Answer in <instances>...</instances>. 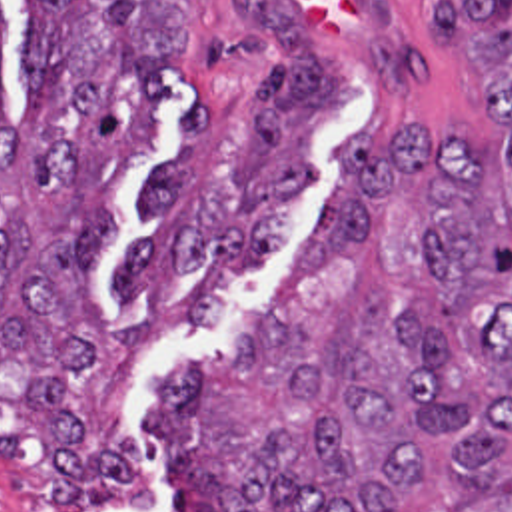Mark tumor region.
Returning <instances> with one entry per match:
<instances>
[{
    "mask_svg": "<svg viewBox=\"0 0 512 512\" xmlns=\"http://www.w3.org/2000/svg\"><path fill=\"white\" fill-rule=\"evenodd\" d=\"M432 34L470 56L474 106L498 142L418 126L376 152L340 146L334 204L248 346L170 374L154 436L172 471L226 512H512V0H426ZM240 22L282 50L234 162L242 206L200 188L202 100L180 156L144 180L154 232L116 294L266 274L290 206L316 174L314 134L348 108L340 72L274 0ZM182 66L178 0H32L6 112L0 0V408L48 465L60 512L144 511L154 479L124 426L94 424L90 386L108 316L96 292L108 194L154 148L164 76Z\"/></svg>",
    "mask_w": 512,
    "mask_h": 512,
    "instance_id": "1",
    "label": "tumor region"
}]
</instances>
